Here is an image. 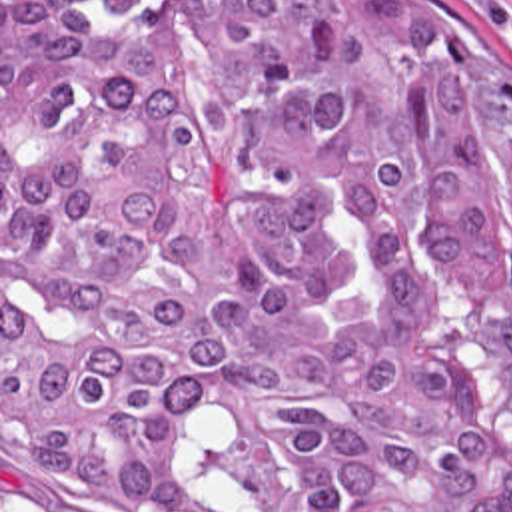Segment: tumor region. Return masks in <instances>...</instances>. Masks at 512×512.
Here are the masks:
<instances>
[{
    "mask_svg": "<svg viewBox=\"0 0 512 512\" xmlns=\"http://www.w3.org/2000/svg\"><path fill=\"white\" fill-rule=\"evenodd\" d=\"M465 320L512 332V78L401 1L2 0L26 496L512 512V396Z\"/></svg>",
    "mask_w": 512,
    "mask_h": 512,
    "instance_id": "obj_1",
    "label": "tumor region"
}]
</instances>
